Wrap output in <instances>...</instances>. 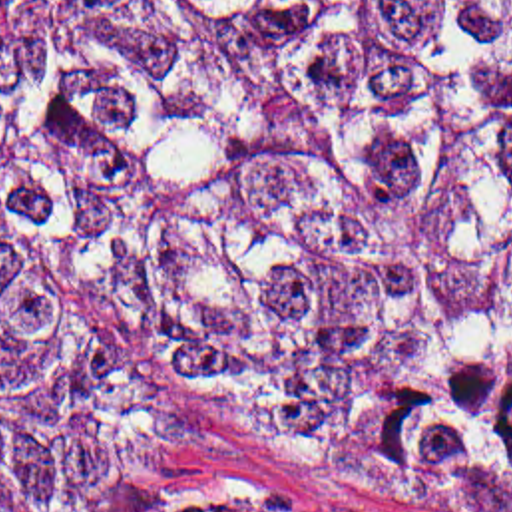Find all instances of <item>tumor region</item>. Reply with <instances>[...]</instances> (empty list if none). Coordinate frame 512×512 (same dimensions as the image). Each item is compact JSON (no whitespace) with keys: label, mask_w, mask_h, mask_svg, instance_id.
I'll use <instances>...</instances> for the list:
<instances>
[{"label":"tumor region","mask_w":512,"mask_h":512,"mask_svg":"<svg viewBox=\"0 0 512 512\" xmlns=\"http://www.w3.org/2000/svg\"><path fill=\"white\" fill-rule=\"evenodd\" d=\"M87 302L248 417L512 489V0H0V512L178 441Z\"/></svg>","instance_id":"tumor-region-1"}]
</instances>
